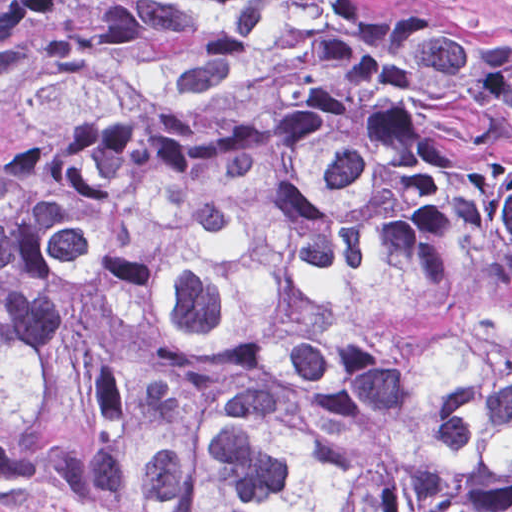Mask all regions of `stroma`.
Returning <instances> with one entry per match:
<instances>
[{
  "label": "stroma",
  "mask_w": 512,
  "mask_h": 512,
  "mask_svg": "<svg viewBox=\"0 0 512 512\" xmlns=\"http://www.w3.org/2000/svg\"><path fill=\"white\" fill-rule=\"evenodd\" d=\"M132 0H0V163L84 114L107 25ZM498 22L512 32V0H359Z\"/></svg>",
  "instance_id": "1"
}]
</instances>
